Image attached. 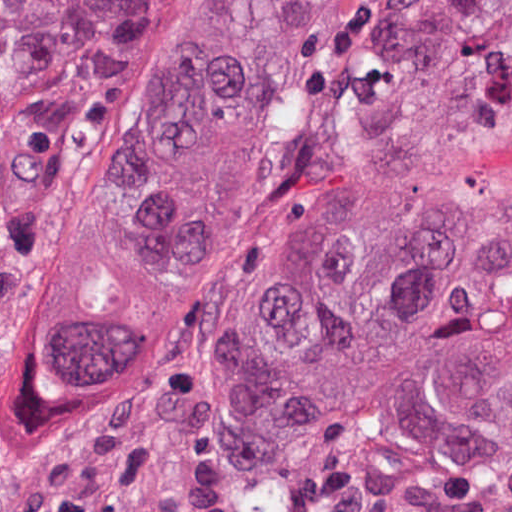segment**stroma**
I'll return each mask as SVG.
<instances>
[{"label": "stroma", "instance_id": "stroma-1", "mask_svg": "<svg viewBox=\"0 0 512 512\" xmlns=\"http://www.w3.org/2000/svg\"><path fill=\"white\" fill-rule=\"evenodd\" d=\"M206 0H140L136 40L78 59L64 118L0 229V512H512V56L448 144L385 310L313 395L233 391L241 325L312 174L367 0L299 141L159 380L44 395L79 232L154 64Z\"/></svg>", "mask_w": 512, "mask_h": 512}]
</instances>
